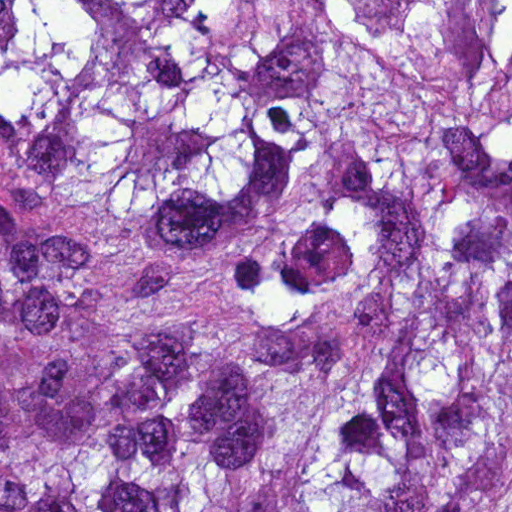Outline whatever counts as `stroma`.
<instances>
[{
	"label": "stroma",
	"instance_id": "stroma-1",
	"mask_svg": "<svg viewBox=\"0 0 512 512\" xmlns=\"http://www.w3.org/2000/svg\"><path fill=\"white\" fill-rule=\"evenodd\" d=\"M20 173L11 144L0 134V203L15 205Z\"/></svg>",
	"mask_w": 512,
	"mask_h": 512
}]
</instances>
